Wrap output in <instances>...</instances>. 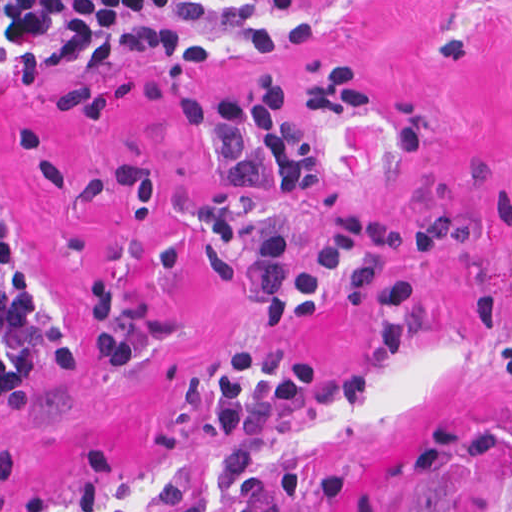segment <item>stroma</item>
I'll return each instance as SVG.
<instances>
[{
	"label": "stroma",
	"mask_w": 512,
	"mask_h": 512,
	"mask_svg": "<svg viewBox=\"0 0 512 512\" xmlns=\"http://www.w3.org/2000/svg\"><path fill=\"white\" fill-rule=\"evenodd\" d=\"M198 1L256 6L278 41L197 26L220 50L12 80L0 0V512H166L171 477L216 507L211 397L268 326L241 257L282 229L299 276L346 211L412 219L389 266L419 281V346L385 352L383 305H340L336 282L289 318L284 349L376 388L244 435L249 483L275 512L293 471L298 512H512V0ZM336 61L366 104L292 107L321 172L283 195L215 106ZM1 234L72 334L3 402Z\"/></svg>",
	"instance_id": "stroma-1"
}]
</instances>
